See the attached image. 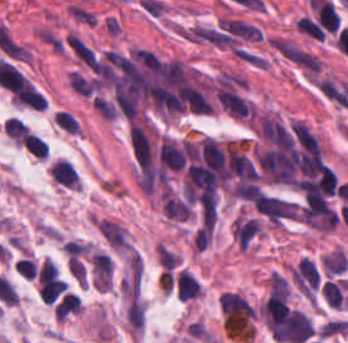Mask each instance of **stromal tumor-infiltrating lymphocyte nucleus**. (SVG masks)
Masks as SVG:
<instances>
[{"label": "stromal tumor-infiltrating lymphocyte nucleus", "mask_w": 348, "mask_h": 343, "mask_svg": "<svg viewBox=\"0 0 348 343\" xmlns=\"http://www.w3.org/2000/svg\"><path fill=\"white\" fill-rule=\"evenodd\" d=\"M50 179L66 189H80V174L69 159L52 158L47 165Z\"/></svg>", "instance_id": "1"}, {"label": "stromal tumor-infiltrating lymphocyte nucleus", "mask_w": 348, "mask_h": 343, "mask_svg": "<svg viewBox=\"0 0 348 343\" xmlns=\"http://www.w3.org/2000/svg\"><path fill=\"white\" fill-rule=\"evenodd\" d=\"M175 291L181 299L195 298L201 289L196 277L188 268H179L174 277Z\"/></svg>", "instance_id": "2"}, {"label": "stromal tumor-infiltrating lymphocyte nucleus", "mask_w": 348, "mask_h": 343, "mask_svg": "<svg viewBox=\"0 0 348 343\" xmlns=\"http://www.w3.org/2000/svg\"><path fill=\"white\" fill-rule=\"evenodd\" d=\"M2 130L11 139L14 144H21L24 141L27 127L21 119L13 116H6Z\"/></svg>", "instance_id": "3"}, {"label": "stromal tumor-infiltrating lymphocyte nucleus", "mask_w": 348, "mask_h": 343, "mask_svg": "<svg viewBox=\"0 0 348 343\" xmlns=\"http://www.w3.org/2000/svg\"><path fill=\"white\" fill-rule=\"evenodd\" d=\"M54 119L56 124L62 128L79 134L80 128L78 121L69 109H55Z\"/></svg>", "instance_id": "4"}, {"label": "stromal tumor-infiltrating lymphocyte nucleus", "mask_w": 348, "mask_h": 343, "mask_svg": "<svg viewBox=\"0 0 348 343\" xmlns=\"http://www.w3.org/2000/svg\"><path fill=\"white\" fill-rule=\"evenodd\" d=\"M25 149L36 157H45L47 145L44 140L28 132L22 140Z\"/></svg>", "instance_id": "5"}]
</instances>
